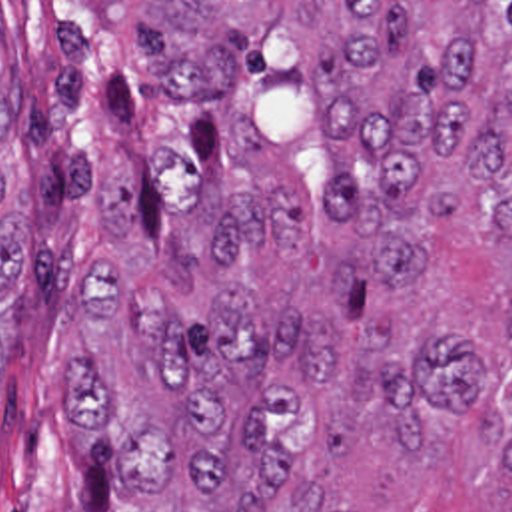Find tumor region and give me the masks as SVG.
I'll list each match as a JSON object with an SVG mask.
<instances>
[{"label": "tumor region", "instance_id": "e687c5a6", "mask_svg": "<svg viewBox=\"0 0 512 512\" xmlns=\"http://www.w3.org/2000/svg\"><path fill=\"white\" fill-rule=\"evenodd\" d=\"M133 32L149 84L197 104L219 158L161 248L93 254L67 437L131 512H355L325 491L355 437L427 457L431 413H467L487 383L457 325L383 331L361 305L423 273L431 224L512 238V2H141ZM19 92L13 66L0 375L33 242ZM481 421L512 471V421Z\"/></svg>", "mask_w": 512, "mask_h": 512}]
</instances>
